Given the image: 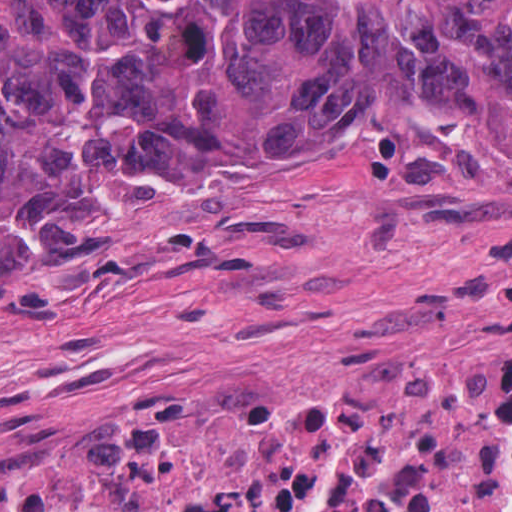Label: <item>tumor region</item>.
<instances>
[{"label": "tumor region", "mask_w": 512, "mask_h": 512, "mask_svg": "<svg viewBox=\"0 0 512 512\" xmlns=\"http://www.w3.org/2000/svg\"><path fill=\"white\" fill-rule=\"evenodd\" d=\"M440 128L512 144V0H429L419 29L348 0H0V300L119 250L98 169Z\"/></svg>", "instance_id": "obj_1"}]
</instances>
